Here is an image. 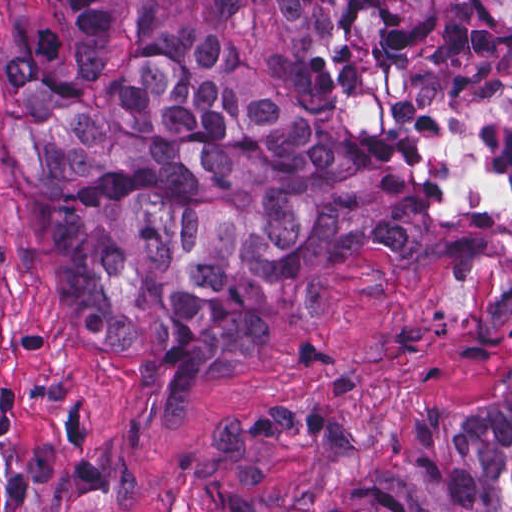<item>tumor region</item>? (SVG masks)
I'll return each instance as SVG.
<instances>
[{
  "instance_id": "e687c5a6",
  "label": "tumor region",
  "mask_w": 512,
  "mask_h": 512,
  "mask_svg": "<svg viewBox=\"0 0 512 512\" xmlns=\"http://www.w3.org/2000/svg\"><path fill=\"white\" fill-rule=\"evenodd\" d=\"M309 32L378 21L410 59L462 61L512 104V1H231ZM4 169L43 224L84 339L204 397L261 296L476 236L425 144L362 140L266 85L207 34L152 37L126 1H24L0 39ZM512 395L414 410L384 456L326 497L229 486L215 512H510Z\"/></svg>"
}]
</instances>
